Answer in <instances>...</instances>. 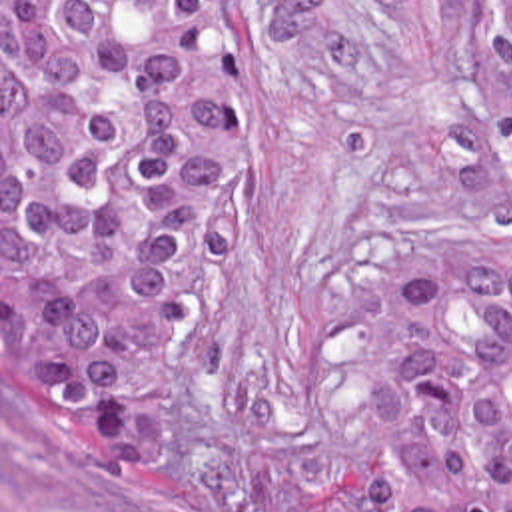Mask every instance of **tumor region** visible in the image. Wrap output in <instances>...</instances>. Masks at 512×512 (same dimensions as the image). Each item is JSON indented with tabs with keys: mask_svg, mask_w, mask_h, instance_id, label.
<instances>
[{
	"mask_svg": "<svg viewBox=\"0 0 512 512\" xmlns=\"http://www.w3.org/2000/svg\"><path fill=\"white\" fill-rule=\"evenodd\" d=\"M512 166V0H481ZM256 170V0H2V394L98 477L174 436L176 356ZM373 512H512V246L383 266Z\"/></svg>",
	"mask_w": 512,
	"mask_h": 512,
	"instance_id": "e687c5a6",
	"label": "tumor region"
}]
</instances>
